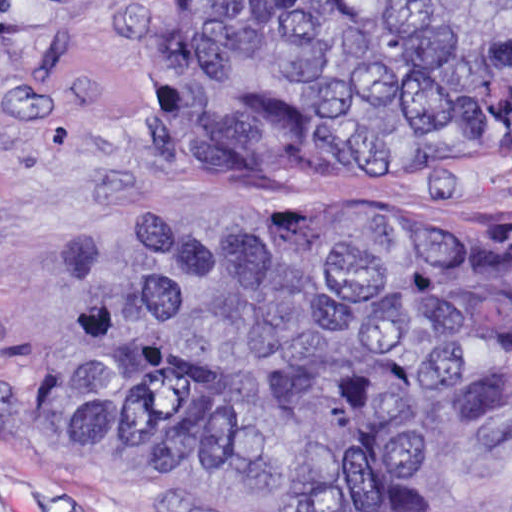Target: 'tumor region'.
<instances>
[{
    "label": "tumor region",
    "mask_w": 512,
    "mask_h": 512,
    "mask_svg": "<svg viewBox=\"0 0 512 512\" xmlns=\"http://www.w3.org/2000/svg\"><path fill=\"white\" fill-rule=\"evenodd\" d=\"M197 165L512 161V0H213L169 53ZM55 451L201 512H420L447 443L512 449V216L478 233L167 222L74 302Z\"/></svg>",
    "instance_id": "e687c5a6"
}]
</instances>
